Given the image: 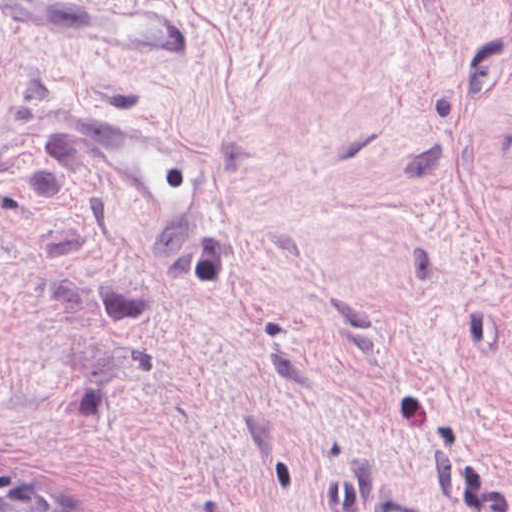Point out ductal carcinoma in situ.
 <instances>
[{"label":"ductal carcinoma in situ","instance_id":"0f090b9a","mask_svg":"<svg viewBox=\"0 0 512 512\" xmlns=\"http://www.w3.org/2000/svg\"><path fill=\"white\" fill-rule=\"evenodd\" d=\"M0 462V512H79L21 471Z\"/></svg>","mask_w":512,"mask_h":512}]
</instances>
